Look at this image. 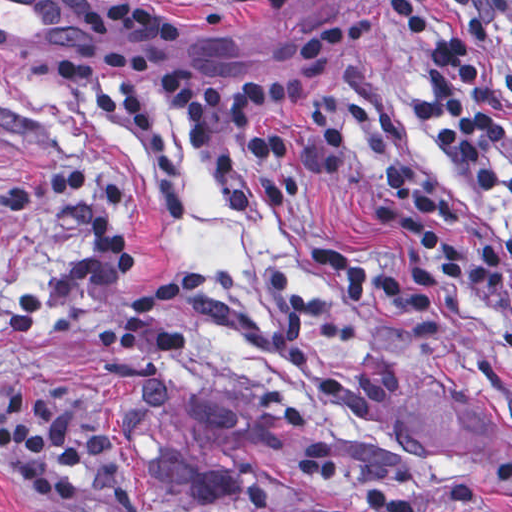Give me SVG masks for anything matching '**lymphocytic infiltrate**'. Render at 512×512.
Listing matches in <instances>:
<instances>
[{
    "mask_svg": "<svg viewBox=\"0 0 512 512\" xmlns=\"http://www.w3.org/2000/svg\"><path fill=\"white\" fill-rule=\"evenodd\" d=\"M71 44L51 64L54 93L133 146L154 178L180 173L176 146L161 118L171 110L188 128L209 169L220 207L283 210L325 181L364 126L353 107L307 128L287 119L324 98L354 46L393 38L410 66L407 109L413 128L459 183L500 207L490 218L387 152L373 169L367 234L386 257L417 272L465 309L512 308V156L500 103L512 108V0H352L324 28L302 30L275 68L253 82L208 80L174 60L183 30L141 0H70ZM186 19L212 21L310 0H155ZM61 195L78 204L84 246L109 276L136 270V248L103 206L91 174L63 169L34 185L0 189V213L22 215ZM205 287L203 275H166L136 291L127 307L93 322L105 349L185 351V333L160 315ZM40 318L29 291L0 318V343L21 340ZM78 401L35 397L15 388L0 427V450L15 454L36 494H79L94 456L79 428ZM298 473L334 484V447L308 444ZM362 500L371 512H415L410 498L379 487Z\"/></svg>",
    "mask_w": 512,
    "mask_h": 512,
    "instance_id": "f902f5d3",
    "label": "lymphocytic infiltrate"
}]
</instances>
